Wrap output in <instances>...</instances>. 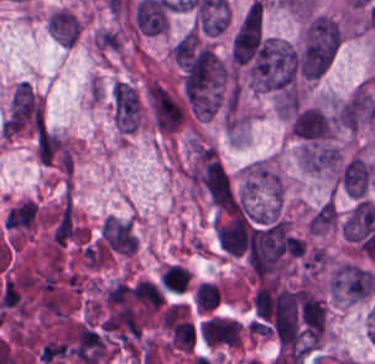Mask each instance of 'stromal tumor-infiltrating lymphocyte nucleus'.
I'll use <instances>...</instances> for the list:
<instances>
[{
  "instance_id": "1",
  "label": "stromal tumor-infiltrating lymphocyte nucleus",
  "mask_w": 375,
  "mask_h": 364,
  "mask_svg": "<svg viewBox=\"0 0 375 364\" xmlns=\"http://www.w3.org/2000/svg\"><path fill=\"white\" fill-rule=\"evenodd\" d=\"M190 272L187 268L170 264L161 274L160 283L164 288L183 291Z\"/></svg>"
},
{
  "instance_id": "2",
  "label": "stromal tumor-infiltrating lymphocyte nucleus",
  "mask_w": 375,
  "mask_h": 364,
  "mask_svg": "<svg viewBox=\"0 0 375 364\" xmlns=\"http://www.w3.org/2000/svg\"><path fill=\"white\" fill-rule=\"evenodd\" d=\"M217 296L218 288L204 282L196 287L195 303L202 310H211L217 305Z\"/></svg>"
}]
</instances>
